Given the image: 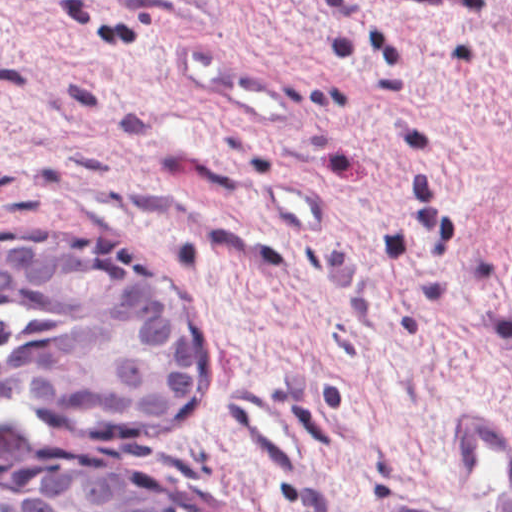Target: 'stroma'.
<instances>
[{"label":"stroma","mask_w":512,"mask_h":512,"mask_svg":"<svg viewBox=\"0 0 512 512\" xmlns=\"http://www.w3.org/2000/svg\"><path fill=\"white\" fill-rule=\"evenodd\" d=\"M202 31L293 100L264 124L178 75ZM331 209L281 236L257 189ZM98 246L210 343L208 400L71 422L200 512H398L448 492L471 407L512 434V0H0V240Z\"/></svg>","instance_id":"stroma-1"}]
</instances>
